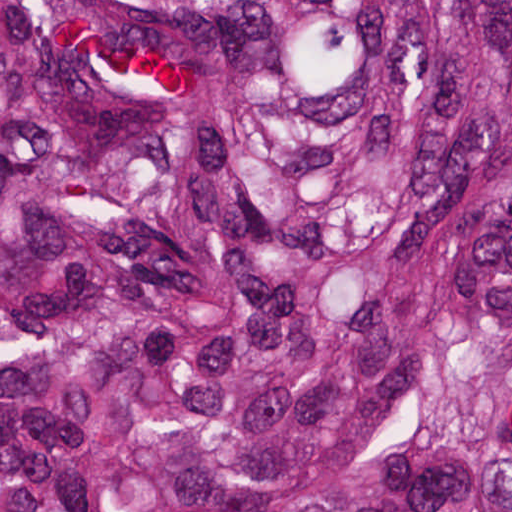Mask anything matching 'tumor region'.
<instances>
[{"mask_svg": "<svg viewBox=\"0 0 512 512\" xmlns=\"http://www.w3.org/2000/svg\"><path fill=\"white\" fill-rule=\"evenodd\" d=\"M0 512H512V0H0Z\"/></svg>", "mask_w": 512, "mask_h": 512, "instance_id": "obj_1", "label": "tumor region"}]
</instances>
